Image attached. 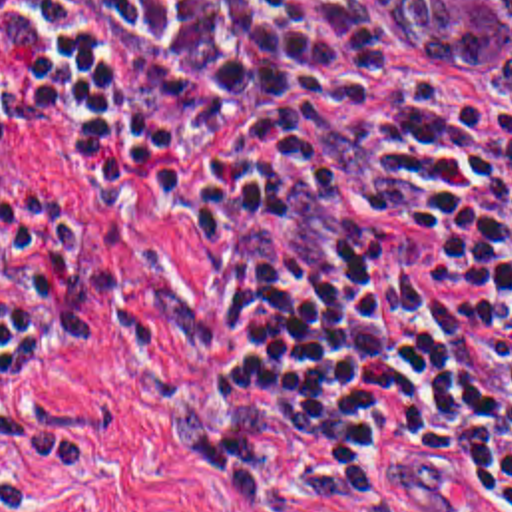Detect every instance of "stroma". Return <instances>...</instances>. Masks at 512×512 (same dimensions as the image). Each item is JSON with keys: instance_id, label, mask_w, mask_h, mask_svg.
I'll use <instances>...</instances> for the list:
<instances>
[{"instance_id": "stroma-1", "label": "stroma", "mask_w": 512, "mask_h": 512, "mask_svg": "<svg viewBox=\"0 0 512 512\" xmlns=\"http://www.w3.org/2000/svg\"><path fill=\"white\" fill-rule=\"evenodd\" d=\"M340 1L392 73L512 131L492 65L436 71L374 1ZM0 61L10 65L2 31ZM4 105L18 143L0 151V304L38 282L56 340L10 388L20 429L0 439V512H239L195 412L209 334L199 232L121 135ZM398 512L512 509L418 491Z\"/></svg>"}]
</instances>
